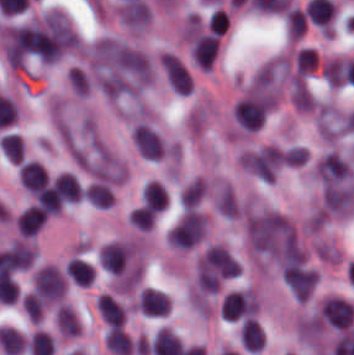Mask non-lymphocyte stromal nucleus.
<instances>
[{
    "mask_svg": "<svg viewBox=\"0 0 354 355\" xmlns=\"http://www.w3.org/2000/svg\"><path fill=\"white\" fill-rule=\"evenodd\" d=\"M202 232V215L193 210H186L170 228L166 241L177 248H190L201 239Z\"/></svg>",
    "mask_w": 354,
    "mask_h": 355,
    "instance_id": "non-lymphocyte-stromal-nucleus-1",
    "label": "non-lymphocyte stromal nucleus"
},
{
    "mask_svg": "<svg viewBox=\"0 0 354 355\" xmlns=\"http://www.w3.org/2000/svg\"><path fill=\"white\" fill-rule=\"evenodd\" d=\"M32 287L34 294L50 303L60 298L64 290V282L51 265H44L38 268Z\"/></svg>",
    "mask_w": 354,
    "mask_h": 355,
    "instance_id": "non-lymphocyte-stromal-nucleus-2",
    "label": "non-lymphocyte stromal nucleus"
},
{
    "mask_svg": "<svg viewBox=\"0 0 354 355\" xmlns=\"http://www.w3.org/2000/svg\"><path fill=\"white\" fill-rule=\"evenodd\" d=\"M204 193V183L201 180L194 179L182 191L179 201L181 209H189Z\"/></svg>",
    "mask_w": 354,
    "mask_h": 355,
    "instance_id": "non-lymphocyte-stromal-nucleus-3",
    "label": "non-lymphocyte stromal nucleus"
},
{
    "mask_svg": "<svg viewBox=\"0 0 354 355\" xmlns=\"http://www.w3.org/2000/svg\"><path fill=\"white\" fill-rule=\"evenodd\" d=\"M57 326L61 335H76L79 332L77 321L71 309L62 305L57 311Z\"/></svg>",
    "mask_w": 354,
    "mask_h": 355,
    "instance_id": "non-lymphocyte-stromal-nucleus-4",
    "label": "non-lymphocyte stromal nucleus"
},
{
    "mask_svg": "<svg viewBox=\"0 0 354 355\" xmlns=\"http://www.w3.org/2000/svg\"><path fill=\"white\" fill-rule=\"evenodd\" d=\"M216 207L224 216L233 218L236 206L232 189L225 186L222 188Z\"/></svg>",
    "mask_w": 354,
    "mask_h": 355,
    "instance_id": "non-lymphocyte-stromal-nucleus-5",
    "label": "non-lymphocyte stromal nucleus"
}]
</instances>
